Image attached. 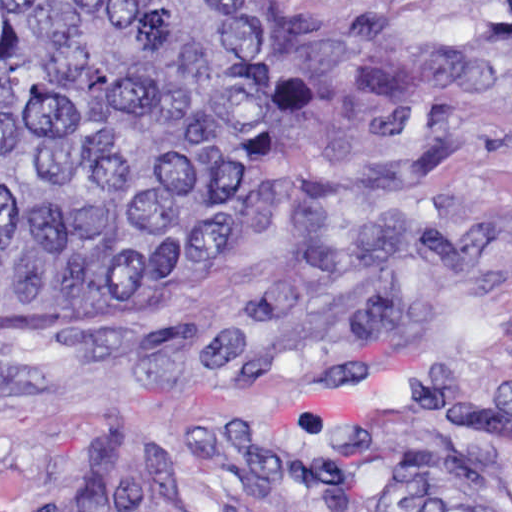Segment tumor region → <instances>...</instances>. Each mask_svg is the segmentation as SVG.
Here are the masks:
<instances>
[{"instance_id":"e687c5a6","label":"tumor region","mask_w":512,"mask_h":512,"mask_svg":"<svg viewBox=\"0 0 512 512\" xmlns=\"http://www.w3.org/2000/svg\"><path fill=\"white\" fill-rule=\"evenodd\" d=\"M368 55L268 0H0V295L172 300L253 239Z\"/></svg>"}]
</instances>
